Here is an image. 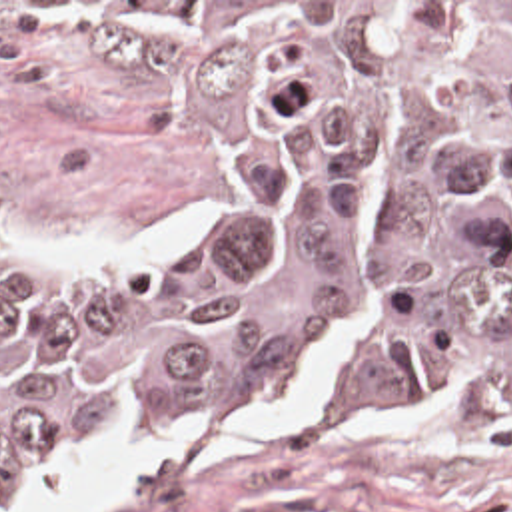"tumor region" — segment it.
<instances>
[{
  "instance_id": "1",
  "label": "tumor region",
  "mask_w": 512,
  "mask_h": 512,
  "mask_svg": "<svg viewBox=\"0 0 512 512\" xmlns=\"http://www.w3.org/2000/svg\"><path fill=\"white\" fill-rule=\"evenodd\" d=\"M192 92L236 188L162 274L0 268V493L146 425L512 435V2H64Z\"/></svg>"
}]
</instances>
